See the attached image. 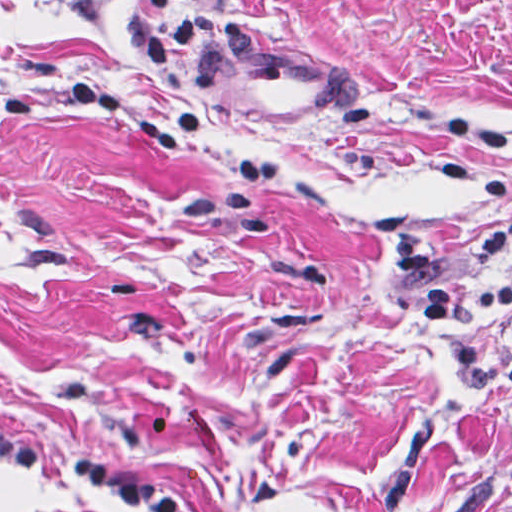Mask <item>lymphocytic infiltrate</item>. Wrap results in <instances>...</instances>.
I'll use <instances>...</instances> for the list:
<instances>
[{
  "label": "lymphocytic infiltrate",
  "mask_w": 512,
  "mask_h": 512,
  "mask_svg": "<svg viewBox=\"0 0 512 512\" xmlns=\"http://www.w3.org/2000/svg\"><path fill=\"white\" fill-rule=\"evenodd\" d=\"M511 237L512 211L486 226L475 241L484 270L471 276L439 271L425 282L424 318L452 369L471 384L512 387V327L495 346L473 339L481 320L512 304V271L503 265ZM0 459L31 475L87 485L141 512H197L160 483L85 456L30 445L2 422Z\"/></svg>",
  "instance_id": "f902f5d3"
}]
</instances>
